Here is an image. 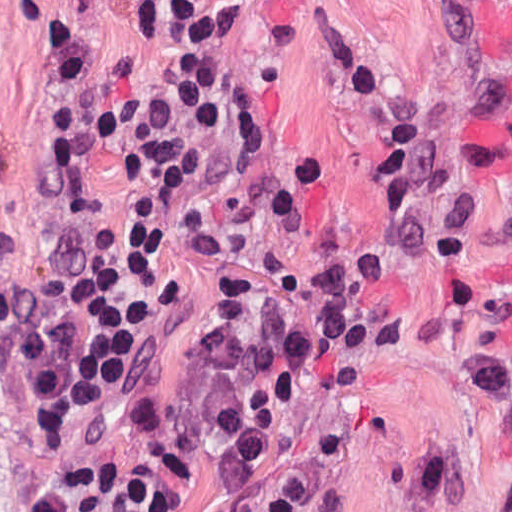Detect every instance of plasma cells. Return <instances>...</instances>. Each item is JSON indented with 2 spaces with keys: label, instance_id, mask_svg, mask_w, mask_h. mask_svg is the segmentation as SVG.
<instances>
[{
  "label": "plasma cells",
  "instance_id": "obj_1",
  "mask_svg": "<svg viewBox=\"0 0 512 512\" xmlns=\"http://www.w3.org/2000/svg\"><path fill=\"white\" fill-rule=\"evenodd\" d=\"M164 23L178 53L206 57L211 0H168ZM326 56L344 80L345 102L373 149L368 182L387 217L368 241L350 237L329 153L289 145L267 128L265 95L249 80L231 98L232 184L224 211L270 216L313 245L297 270L299 289L326 310L335 336L363 352H393L410 339V319L391 291L390 270L413 258L428 270L435 301L468 333L466 358L487 413L512 430V310L476 283L471 254L503 229L481 213L467 179L434 165L443 138L463 136L512 113V76L497 77L427 113L403 108L368 48L333 28ZM417 505L437 512H512L509 488L476 483L442 442L410 457Z\"/></svg>",
  "mask_w": 512,
  "mask_h": 512
}]
</instances>
